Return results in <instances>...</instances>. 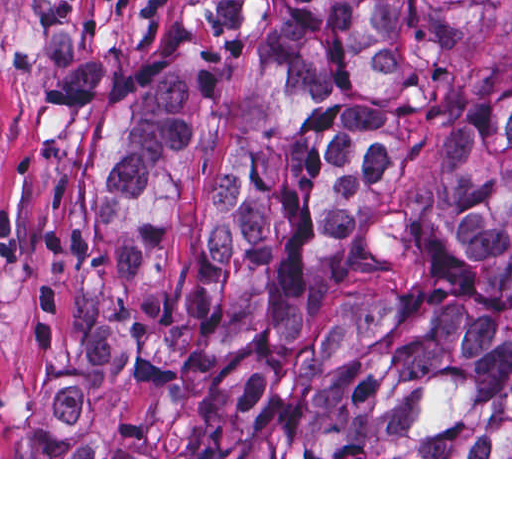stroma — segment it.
Segmentation results:
<instances>
[{
  "label": "stroma",
  "instance_id": "1",
  "mask_svg": "<svg viewBox=\"0 0 512 512\" xmlns=\"http://www.w3.org/2000/svg\"><path fill=\"white\" fill-rule=\"evenodd\" d=\"M192 16L193 0H0V459H512L186 457L204 408L168 375H123L82 405L114 457H21L20 385L68 346L84 206L113 99Z\"/></svg>",
  "mask_w": 512,
  "mask_h": 512
}]
</instances>
